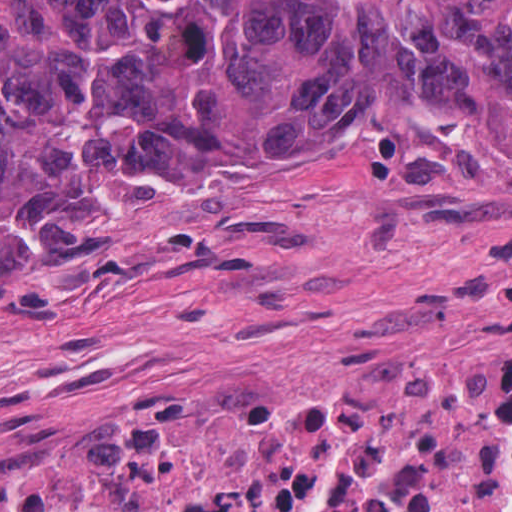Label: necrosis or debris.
Here are the masks:
<instances>
[{"mask_svg":"<svg viewBox=\"0 0 512 512\" xmlns=\"http://www.w3.org/2000/svg\"><path fill=\"white\" fill-rule=\"evenodd\" d=\"M409 29L429 0H348ZM512 358L347 377L231 375L74 473L0 480V512H504Z\"/></svg>","mask_w":512,"mask_h":512,"instance_id":"4bbe7bcc","label":"necrosis or debris"}]
</instances>
